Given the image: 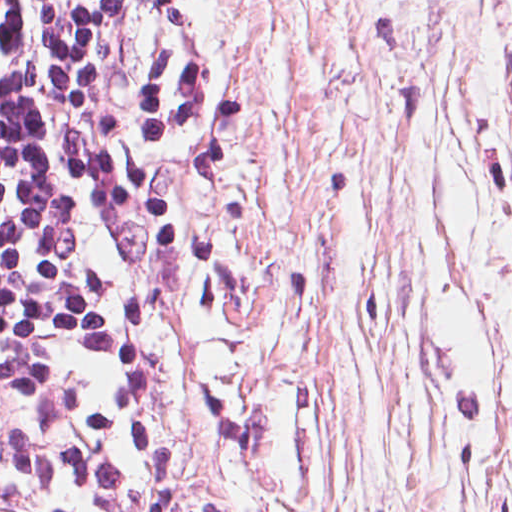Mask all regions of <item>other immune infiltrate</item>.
Returning <instances> with one entry per match:
<instances>
[{"instance_id": "bc1004c8", "label": "other immune infiltrate", "mask_w": 512, "mask_h": 512, "mask_svg": "<svg viewBox=\"0 0 512 512\" xmlns=\"http://www.w3.org/2000/svg\"><path fill=\"white\" fill-rule=\"evenodd\" d=\"M166 466V376L150 341L132 387L110 459L85 512H152Z\"/></svg>"}]
</instances>
